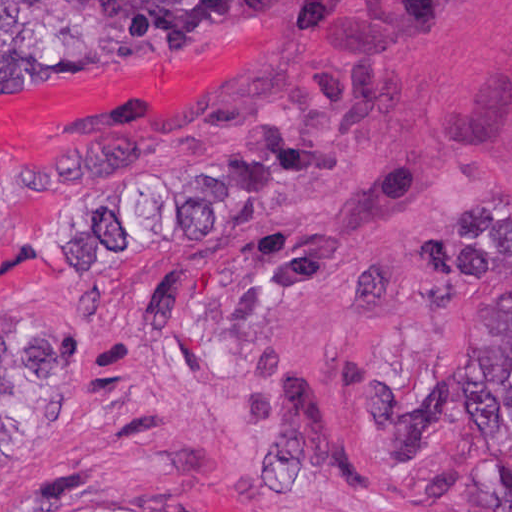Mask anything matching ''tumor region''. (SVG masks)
<instances>
[{
    "mask_svg": "<svg viewBox=\"0 0 512 512\" xmlns=\"http://www.w3.org/2000/svg\"><path fill=\"white\" fill-rule=\"evenodd\" d=\"M291 0H0V99L53 76L156 57ZM470 476L485 512H512V328L461 362ZM75 401V351L56 326L0 331V483L20 477Z\"/></svg>",
    "mask_w": 512,
    "mask_h": 512,
    "instance_id": "tumor-region-1",
    "label": "tumor region"
}]
</instances>
